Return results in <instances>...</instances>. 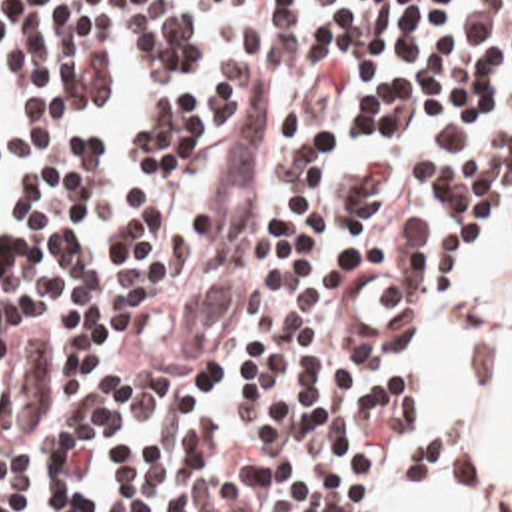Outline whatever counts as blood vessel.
<instances>
[{"instance_id":"blood-vessel-1","label":"blood vessel","mask_w":512,"mask_h":512,"mask_svg":"<svg viewBox=\"0 0 512 512\" xmlns=\"http://www.w3.org/2000/svg\"><path fill=\"white\" fill-rule=\"evenodd\" d=\"M269 144V90L261 76L241 98L229 128V154L171 328V354H197L229 316L259 224V168ZM340 306L362 338H410L418 324V288L388 272H342Z\"/></svg>"}]
</instances>
